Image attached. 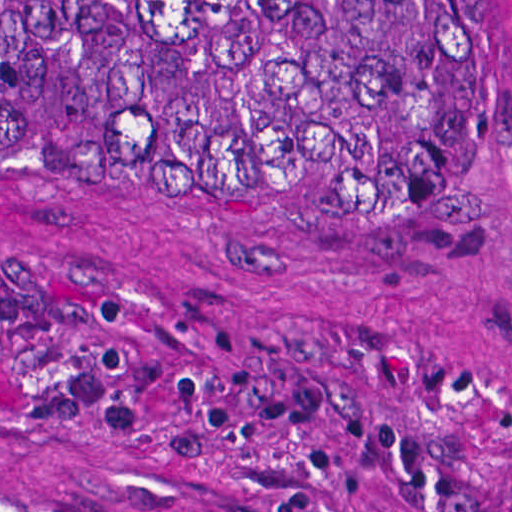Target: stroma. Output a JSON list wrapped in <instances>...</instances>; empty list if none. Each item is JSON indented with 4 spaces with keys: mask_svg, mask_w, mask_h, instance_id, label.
I'll list each match as a JSON object with an SVG mask.
<instances>
[{
    "mask_svg": "<svg viewBox=\"0 0 512 512\" xmlns=\"http://www.w3.org/2000/svg\"><path fill=\"white\" fill-rule=\"evenodd\" d=\"M470 177L0 146V467L79 512H512V0Z\"/></svg>",
    "mask_w": 512,
    "mask_h": 512,
    "instance_id": "35a3bbf8",
    "label": "stroma"
}]
</instances>
